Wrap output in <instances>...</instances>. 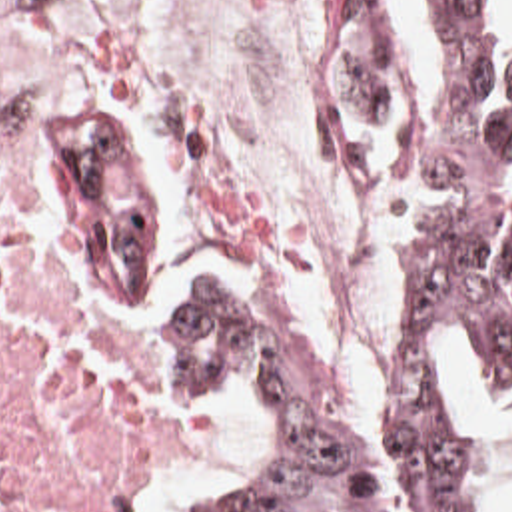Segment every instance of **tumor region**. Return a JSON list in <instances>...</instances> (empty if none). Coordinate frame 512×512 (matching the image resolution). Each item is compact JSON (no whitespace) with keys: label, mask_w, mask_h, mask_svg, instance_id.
Returning <instances> with one entry per match:
<instances>
[{"label":"tumor region","mask_w":512,"mask_h":512,"mask_svg":"<svg viewBox=\"0 0 512 512\" xmlns=\"http://www.w3.org/2000/svg\"><path fill=\"white\" fill-rule=\"evenodd\" d=\"M426 66L385 16H337L325 128L397 226L387 332L357 432L337 428L311 354L249 274L207 262L169 318L165 378L249 382L275 450L201 512H452L454 348L512 392V0H403Z\"/></svg>","instance_id":"e687c5a6"}]
</instances>
